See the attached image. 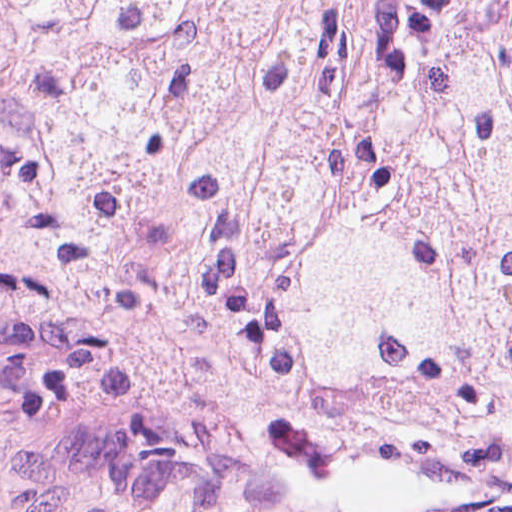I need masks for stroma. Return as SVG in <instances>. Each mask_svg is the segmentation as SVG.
Wrapping results in <instances>:
<instances>
[{"label":"stroma","mask_w":512,"mask_h":512,"mask_svg":"<svg viewBox=\"0 0 512 512\" xmlns=\"http://www.w3.org/2000/svg\"><path fill=\"white\" fill-rule=\"evenodd\" d=\"M368 490L395 512H512V421L439 438L356 411L308 366L206 396L0 321V512H294Z\"/></svg>","instance_id":"35a3bbf8"}]
</instances>
